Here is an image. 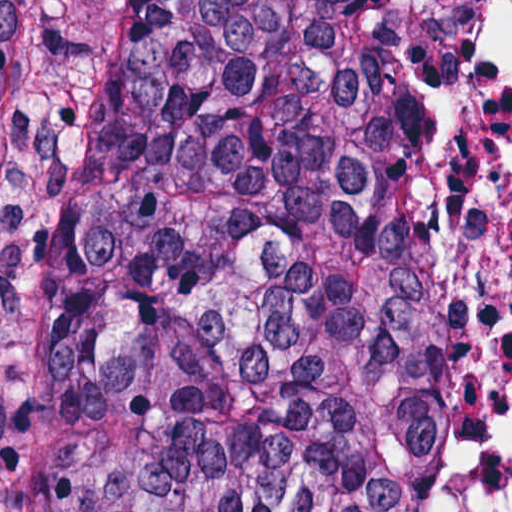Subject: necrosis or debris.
<instances>
[{
	"label": "necrosis or debris",
	"instance_id": "necrosis-or-debris-1",
	"mask_svg": "<svg viewBox=\"0 0 512 512\" xmlns=\"http://www.w3.org/2000/svg\"><path fill=\"white\" fill-rule=\"evenodd\" d=\"M442 108L476 187V340L435 512H512V0H435Z\"/></svg>",
	"mask_w": 512,
	"mask_h": 512
}]
</instances>
